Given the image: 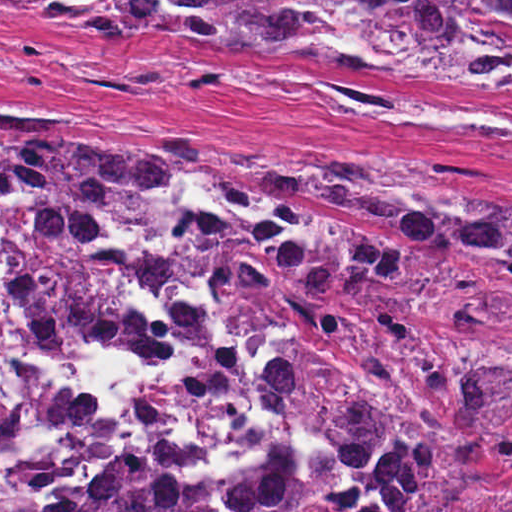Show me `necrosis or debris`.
Masks as SVG:
<instances>
[{
    "label": "necrosis or debris",
    "mask_w": 512,
    "mask_h": 512,
    "mask_svg": "<svg viewBox=\"0 0 512 512\" xmlns=\"http://www.w3.org/2000/svg\"><path fill=\"white\" fill-rule=\"evenodd\" d=\"M0 350L46 422L0 458V512H62L101 464L181 486L258 468L256 386L223 350L190 205L102 222L0 193Z\"/></svg>",
    "instance_id": "necrosis-or-debris-1"
}]
</instances>
